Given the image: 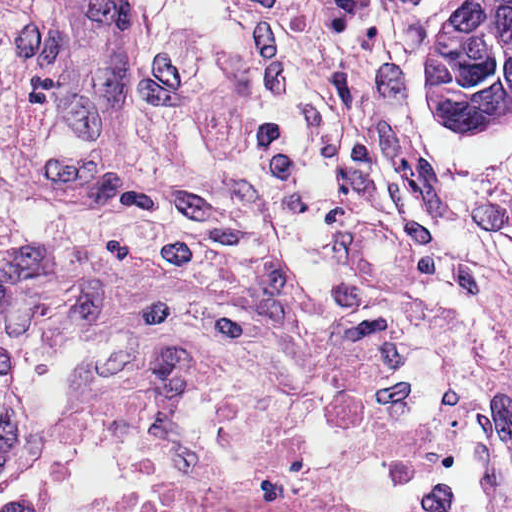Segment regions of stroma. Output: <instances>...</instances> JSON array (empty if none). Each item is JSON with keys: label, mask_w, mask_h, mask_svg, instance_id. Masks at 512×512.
I'll return each mask as SVG.
<instances>
[{"label": "stroma", "mask_w": 512, "mask_h": 512, "mask_svg": "<svg viewBox=\"0 0 512 512\" xmlns=\"http://www.w3.org/2000/svg\"><path fill=\"white\" fill-rule=\"evenodd\" d=\"M0 512H430L225 51L207 198L0 214Z\"/></svg>", "instance_id": "stroma-1"}]
</instances>
